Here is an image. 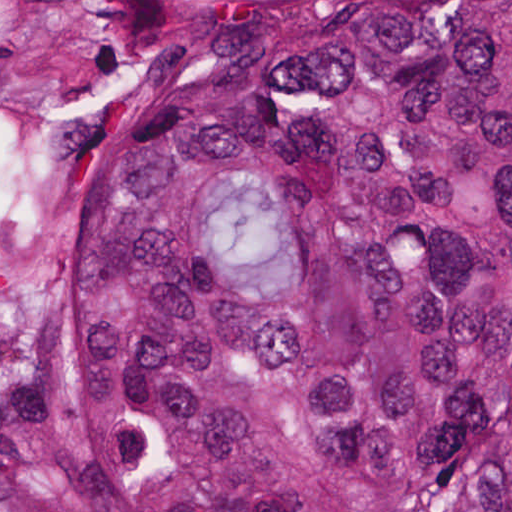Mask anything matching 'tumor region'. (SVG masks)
I'll use <instances>...</instances> for the list:
<instances>
[{"mask_svg": "<svg viewBox=\"0 0 512 512\" xmlns=\"http://www.w3.org/2000/svg\"><path fill=\"white\" fill-rule=\"evenodd\" d=\"M0 512H512V0H0Z\"/></svg>", "mask_w": 512, "mask_h": 512, "instance_id": "tumor-region-1", "label": "tumor region"}]
</instances>
